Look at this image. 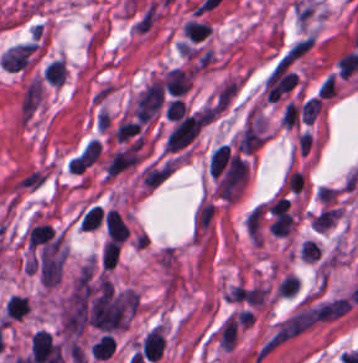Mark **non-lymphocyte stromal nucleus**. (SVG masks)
<instances>
[{"instance_id":"obj_6","label":"non-lymphocyte stromal nucleus","mask_w":358,"mask_h":363,"mask_svg":"<svg viewBox=\"0 0 358 363\" xmlns=\"http://www.w3.org/2000/svg\"><path fill=\"white\" fill-rule=\"evenodd\" d=\"M184 34L188 39L200 41L211 31L210 23L205 21L188 20L183 26Z\"/></svg>"},{"instance_id":"obj_5","label":"non-lymphocyte stromal nucleus","mask_w":358,"mask_h":363,"mask_svg":"<svg viewBox=\"0 0 358 363\" xmlns=\"http://www.w3.org/2000/svg\"><path fill=\"white\" fill-rule=\"evenodd\" d=\"M46 172L39 167H32L17 177L15 186L17 188L34 190L45 182Z\"/></svg>"},{"instance_id":"obj_2","label":"non-lymphocyte stromal nucleus","mask_w":358,"mask_h":363,"mask_svg":"<svg viewBox=\"0 0 358 363\" xmlns=\"http://www.w3.org/2000/svg\"><path fill=\"white\" fill-rule=\"evenodd\" d=\"M35 48L36 43L30 41L17 43L13 47L7 49L1 56L4 68L16 72L24 68L28 64Z\"/></svg>"},{"instance_id":"obj_1","label":"non-lymphocyte stromal nucleus","mask_w":358,"mask_h":363,"mask_svg":"<svg viewBox=\"0 0 358 363\" xmlns=\"http://www.w3.org/2000/svg\"><path fill=\"white\" fill-rule=\"evenodd\" d=\"M164 84L162 80L150 83L139 95L136 101V116L138 121L150 119L162 104Z\"/></svg>"},{"instance_id":"obj_3","label":"non-lymphocyte stromal nucleus","mask_w":358,"mask_h":363,"mask_svg":"<svg viewBox=\"0 0 358 363\" xmlns=\"http://www.w3.org/2000/svg\"><path fill=\"white\" fill-rule=\"evenodd\" d=\"M158 14L159 7L152 0L147 2L132 20L131 29L138 34H146L156 22Z\"/></svg>"},{"instance_id":"obj_7","label":"non-lymphocyte stromal nucleus","mask_w":358,"mask_h":363,"mask_svg":"<svg viewBox=\"0 0 358 363\" xmlns=\"http://www.w3.org/2000/svg\"><path fill=\"white\" fill-rule=\"evenodd\" d=\"M298 113L299 107L297 103L288 100L281 114V122L290 126L297 124Z\"/></svg>"},{"instance_id":"obj_4","label":"non-lymphocyte stromal nucleus","mask_w":358,"mask_h":363,"mask_svg":"<svg viewBox=\"0 0 358 363\" xmlns=\"http://www.w3.org/2000/svg\"><path fill=\"white\" fill-rule=\"evenodd\" d=\"M40 79H33L26 87L22 97V112L26 120L34 108L37 106L40 97Z\"/></svg>"}]
</instances>
